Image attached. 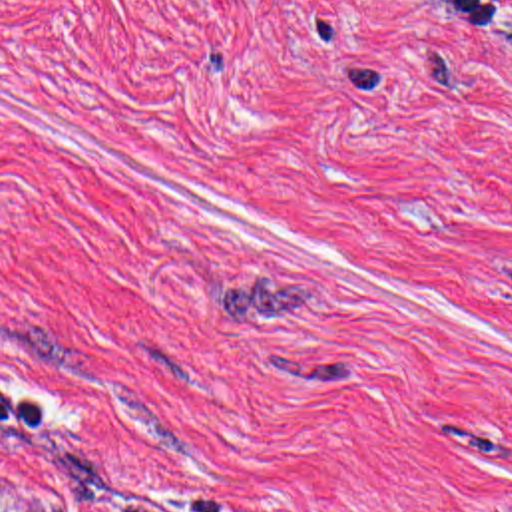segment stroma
<instances>
[{"instance_id":"35a3bbf8","label":"stroma","mask_w":512,"mask_h":512,"mask_svg":"<svg viewBox=\"0 0 512 512\" xmlns=\"http://www.w3.org/2000/svg\"><path fill=\"white\" fill-rule=\"evenodd\" d=\"M0 512H512V0H0Z\"/></svg>"}]
</instances>
